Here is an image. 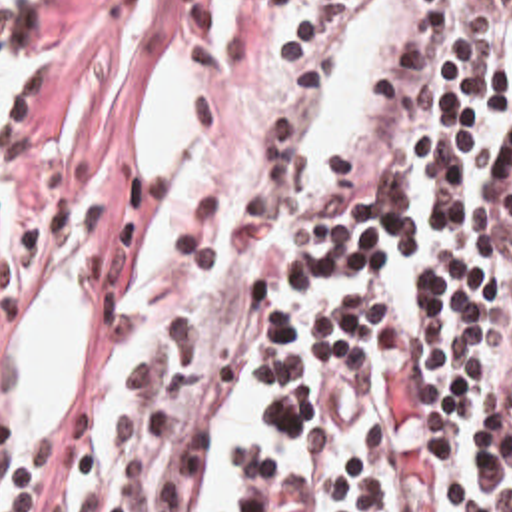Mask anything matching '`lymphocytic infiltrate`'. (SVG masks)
<instances>
[{"label": "lymphocytic infiltrate", "instance_id": "obj_1", "mask_svg": "<svg viewBox=\"0 0 512 512\" xmlns=\"http://www.w3.org/2000/svg\"><path fill=\"white\" fill-rule=\"evenodd\" d=\"M48 0H0V65L42 59ZM347 0H213L201 153L138 175L88 299V368L0 512H512V0H439L381 193L335 227L277 197L281 129ZM26 153V99L0 185ZM263 426L195 482L243 370Z\"/></svg>", "mask_w": 512, "mask_h": 512}]
</instances>
